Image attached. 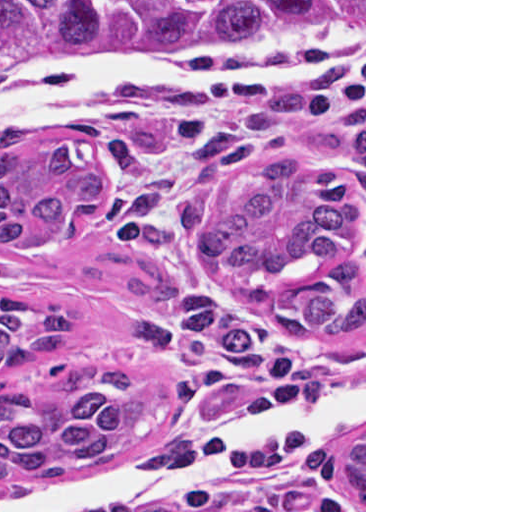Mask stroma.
<instances>
[{"label":"stroma","mask_w":512,"mask_h":512,"mask_svg":"<svg viewBox=\"0 0 512 512\" xmlns=\"http://www.w3.org/2000/svg\"><path fill=\"white\" fill-rule=\"evenodd\" d=\"M347 72L263 87L97 94L24 121L41 147L79 140L105 194L55 242L0 252V290L82 318L48 365L115 369L170 392V414L126 450L39 483L0 485V512H366V0ZM286 154L332 162L364 196V325L288 334L255 301L201 275V227L239 172ZM364 436V509L347 451Z\"/></svg>","instance_id":"35a3bbf8"}]
</instances>
